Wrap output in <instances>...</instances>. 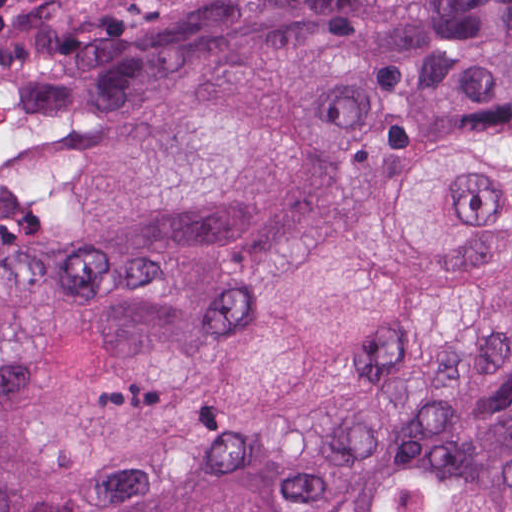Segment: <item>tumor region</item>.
<instances>
[{
	"instance_id": "tumor-region-1",
	"label": "tumor region",
	"mask_w": 512,
	"mask_h": 512,
	"mask_svg": "<svg viewBox=\"0 0 512 512\" xmlns=\"http://www.w3.org/2000/svg\"><path fill=\"white\" fill-rule=\"evenodd\" d=\"M0 124V512H512V0H77Z\"/></svg>"
}]
</instances>
